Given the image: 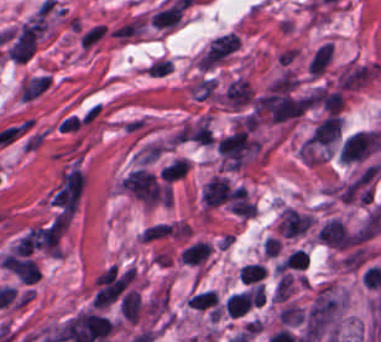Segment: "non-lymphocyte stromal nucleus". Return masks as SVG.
<instances>
[{"mask_svg":"<svg viewBox=\"0 0 381 342\" xmlns=\"http://www.w3.org/2000/svg\"><path fill=\"white\" fill-rule=\"evenodd\" d=\"M147 29L143 12H135L120 18L109 28L113 41L119 45H129L139 40Z\"/></svg>","mask_w":381,"mask_h":342,"instance_id":"obj_1","label":"non-lymphocyte stromal nucleus"},{"mask_svg":"<svg viewBox=\"0 0 381 342\" xmlns=\"http://www.w3.org/2000/svg\"><path fill=\"white\" fill-rule=\"evenodd\" d=\"M107 33V23L95 22L83 26L78 37L80 49L87 52L92 50L107 36Z\"/></svg>","mask_w":381,"mask_h":342,"instance_id":"obj_3","label":"non-lymphocyte stromal nucleus"},{"mask_svg":"<svg viewBox=\"0 0 381 342\" xmlns=\"http://www.w3.org/2000/svg\"><path fill=\"white\" fill-rule=\"evenodd\" d=\"M185 7V4L176 0L155 12L150 21L159 29H171L179 24Z\"/></svg>","mask_w":381,"mask_h":342,"instance_id":"obj_2","label":"non-lymphocyte stromal nucleus"}]
</instances>
